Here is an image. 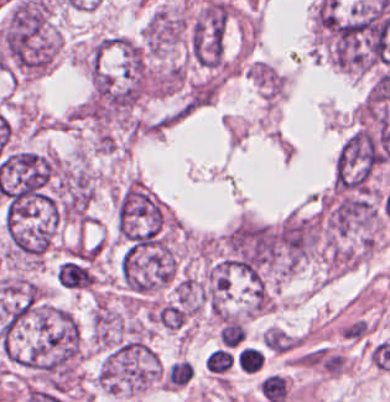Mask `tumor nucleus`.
Listing matches in <instances>:
<instances>
[{"label": "tumor nucleus", "instance_id": "tumor-nucleus-2", "mask_svg": "<svg viewBox=\"0 0 390 402\" xmlns=\"http://www.w3.org/2000/svg\"><path fill=\"white\" fill-rule=\"evenodd\" d=\"M376 136L359 128L341 145L334 163V185L343 190H364L381 163Z\"/></svg>", "mask_w": 390, "mask_h": 402}, {"label": "tumor nucleus", "instance_id": "tumor-nucleus-1", "mask_svg": "<svg viewBox=\"0 0 390 402\" xmlns=\"http://www.w3.org/2000/svg\"><path fill=\"white\" fill-rule=\"evenodd\" d=\"M165 213L158 198L140 184L128 182L117 197L115 224L126 246L152 245L161 238Z\"/></svg>", "mask_w": 390, "mask_h": 402}, {"label": "tumor nucleus", "instance_id": "tumor-nucleus-3", "mask_svg": "<svg viewBox=\"0 0 390 402\" xmlns=\"http://www.w3.org/2000/svg\"><path fill=\"white\" fill-rule=\"evenodd\" d=\"M226 26L225 3L209 0L189 27L190 59L213 68L220 66L224 56Z\"/></svg>", "mask_w": 390, "mask_h": 402}]
</instances>
